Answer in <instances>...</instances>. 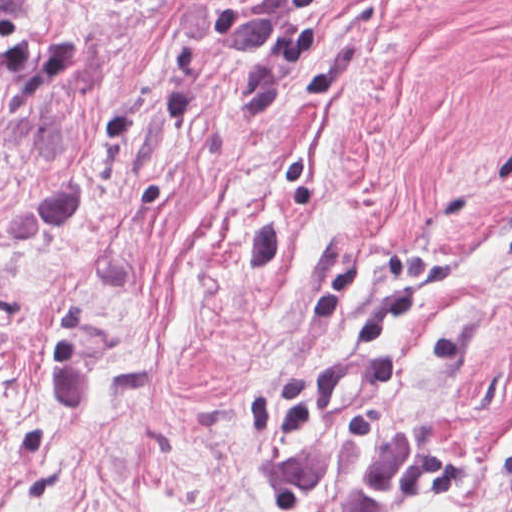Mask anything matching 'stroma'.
I'll use <instances>...</instances> for the list:
<instances>
[{
	"instance_id": "obj_1",
	"label": "stroma",
	"mask_w": 512,
	"mask_h": 512,
	"mask_svg": "<svg viewBox=\"0 0 512 512\" xmlns=\"http://www.w3.org/2000/svg\"><path fill=\"white\" fill-rule=\"evenodd\" d=\"M0 512H512V0H0ZM225 1H280L221 57Z\"/></svg>"
}]
</instances>
